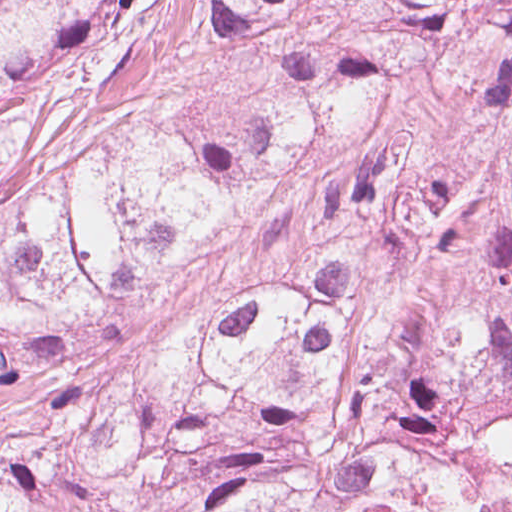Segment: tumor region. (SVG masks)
<instances>
[{
    "mask_svg": "<svg viewBox=\"0 0 512 512\" xmlns=\"http://www.w3.org/2000/svg\"><path fill=\"white\" fill-rule=\"evenodd\" d=\"M415 72L450 179L355 197L150 370L80 367ZM0 387V512H512V0H0Z\"/></svg>",
    "mask_w": 512,
    "mask_h": 512,
    "instance_id": "e687c5a6",
    "label": "tumor region"
}]
</instances>
